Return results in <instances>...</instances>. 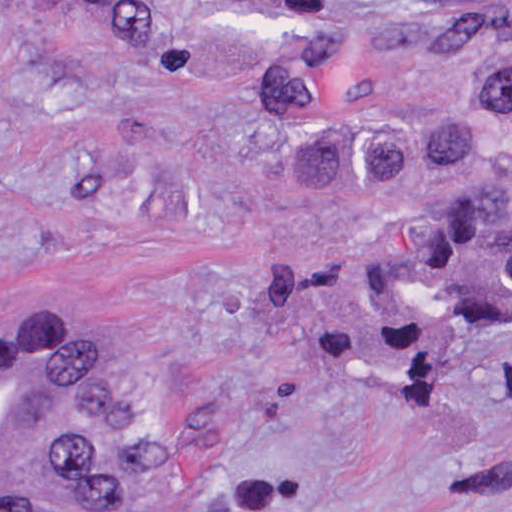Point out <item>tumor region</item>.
<instances>
[{"label":"tumor region","instance_id":"obj_1","mask_svg":"<svg viewBox=\"0 0 512 512\" xmlns=\"http://www.w3.org/2000/svg\"><path fill=\"white\" fill-rule=\"evenodd\" d=\"M325 3L303 29L266 145L321 200L486 172L483 205L385 239L372 298L387 338L435 348L512 316V1ZM244 494L158 473L156 414L136 388V338L80 457L0 512H239Z\"/></svg>","mask_w":512,"mask_h":512}]
</instances>
